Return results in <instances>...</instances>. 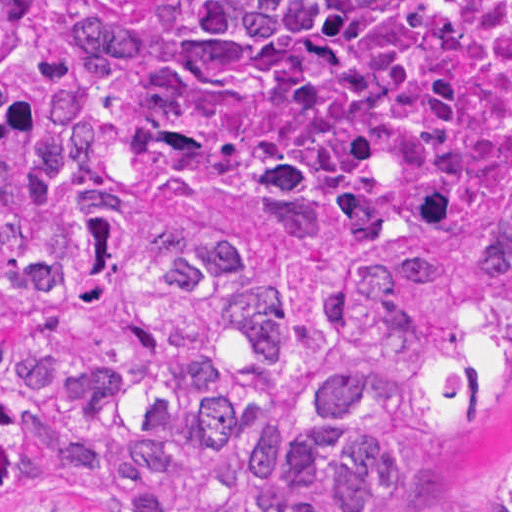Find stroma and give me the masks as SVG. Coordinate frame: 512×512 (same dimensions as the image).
<instances>
[{
  "instance_id": "stroma-1",
  "label": "stroma",
  "mask_w": 512,
  "mask_h": 512,
  "mask_svg": "<svg viewBox=\"0 0 512 512\" xmlns=\"http://www.w3.org/2000/svg\"><path fill=\"white\" fill-rule=\"evenodd\" d=\"M507 348L510 395L488 416L438 430L422 491L390 512H492L490 495L512 471V327Z\"/></svg>"
}]
</instances>
